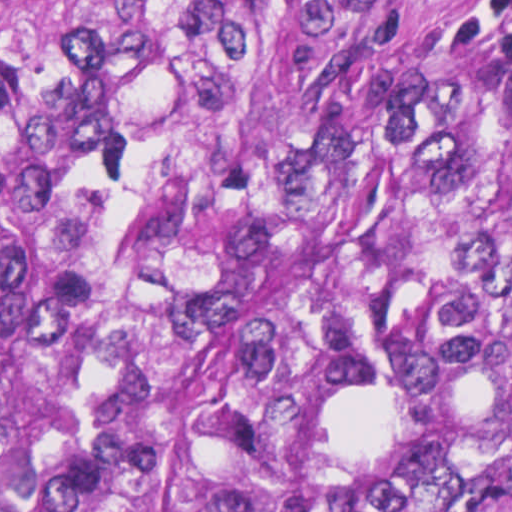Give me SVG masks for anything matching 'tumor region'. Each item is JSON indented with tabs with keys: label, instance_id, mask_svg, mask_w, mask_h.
Instances as JSON below:
<instances>
[{
	"label": "tumor region",
	"instance_id": "e687c5a6",
	"mask_svg": "<svg viewBox=\"0 0 512 512\" xmlns=\"http://www.w3.org/2000/svg\"><path fill=\"white\" fill-rule=\"evenodd\" d=\"M0 512H512V78L436 0H0Z\"/></svg>",
	"mask_w": 512,
	"mask_h": 512
}]
</instances>
